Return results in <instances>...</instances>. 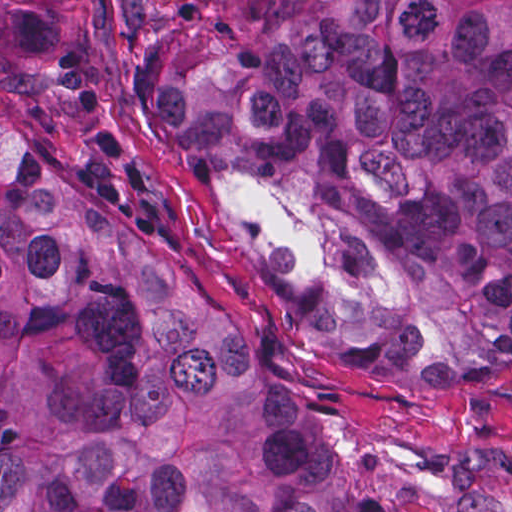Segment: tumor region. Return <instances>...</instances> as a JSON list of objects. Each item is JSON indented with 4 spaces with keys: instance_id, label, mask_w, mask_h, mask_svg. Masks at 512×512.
I'll return each mask as SVG.
<instances>
[{
    "instance_id": "obj_1",
    "label": "tumor region",
    "mask_w": 512,
    "mask_h": 512,
    "mask_svg": "<svg viewBox=\"0 0 512 512\" xmlns=\"http://www.w3.org/2000/svg\"><path fill=\"white\" fill-rule=\"evenodd\" d=\"M63 2L1 0V512H375L204 298ZM128 90L315 365L512 381V0H128Z\"/></svg>"
}]
</instances>
